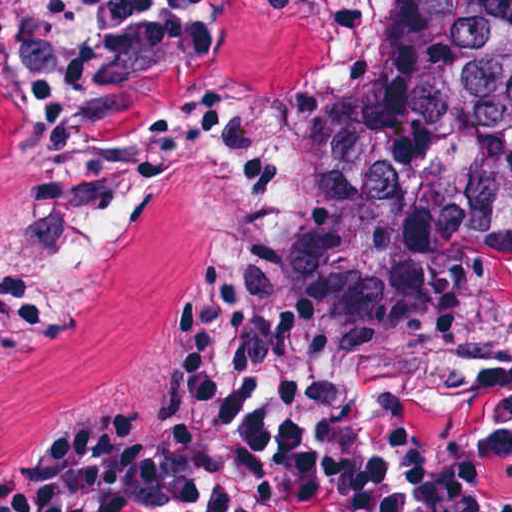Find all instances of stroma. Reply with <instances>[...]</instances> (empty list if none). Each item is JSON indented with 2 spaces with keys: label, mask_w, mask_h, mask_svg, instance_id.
<instances>
[{
  "label": "stroma",
  "mask_w": 512,
  "mask_h": 512,
  "mask_svg": "<svg viewBox=\"0 0 512 512\" xmlns=\"http://www.w3.org/2000/svg\"><path fill=\"white\" fill-rule=\"evenodd\" d=\"M315 280L356 387L380 414L487 429L502 386L512 382V334L486 350H431L370 339L349 287V182L320 226Z\"/></svg>",
  "instance_id": "35a3bbf8"
}]
</instances>
